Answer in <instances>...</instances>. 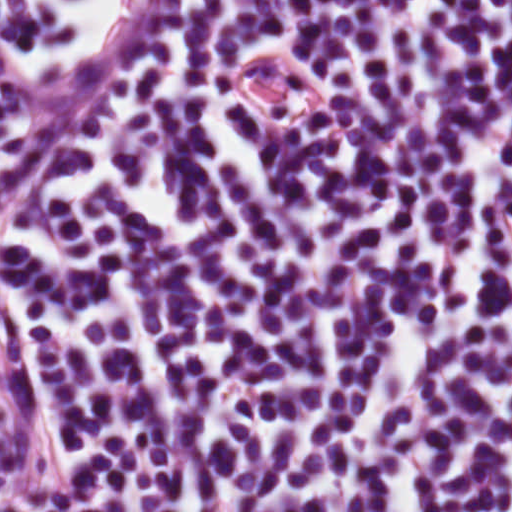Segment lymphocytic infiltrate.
I'll return each instance as SVG.
<instances>
[{
    "mask_svg": "<svg viewBox=\"0 0 512 512\" xmlns=\"http://www.w3.org/2000/svg\"><path fill=\"white\" fill-rule=\"evenodd\" d=\"M0 512H402L174 0H0Z\"/></svg>",
    "mask_w": 512,
    "mask_h": 512,
    "instance_id": "obj_1",
    "label": "lymphocytic infiltrate"
}]
</instances>
